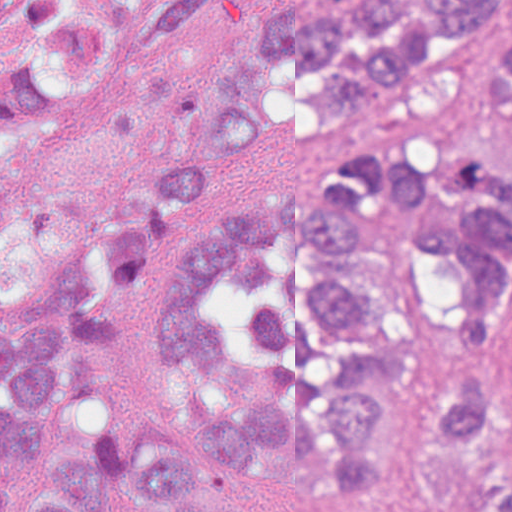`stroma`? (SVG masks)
<instances>
[{"mask_svg":"<svg viewBox=\"0 0 512 512\" xmlns=\"http://www.w3.org/2000/svg\"><path fill=\"white\" fill-rule=\"evenodd\" d=\"M119 44L100 81L82 96L39 111L30 131L0 145V277L7 313L30 277L61 254L137 218L158 222L160 252L190 246L225 210L303 196L326 182V148L303 123L272 134L245 158L228 196L205 205L164 200V176L200 157L204 116L230 58L259 22L311 0H214L194 26L151 43L183 0H112ZM468 59L455 129L462 143L512 166V101L484 98V65L512 32V6ZM502 387L512 389V337ZM413 387L386 386L388 465L382 504L311 491L268 493L251 512H452L440 477L413 449ZM79 426H119L143 456L185 441L154 379L151 309L118 311L115 348ZM512 470V447L502 451Z\"/></svg>","mask_w":512,"mask_h":512,"instance_id":"35a3bbf8","label":"stroma"}]
</instances>
